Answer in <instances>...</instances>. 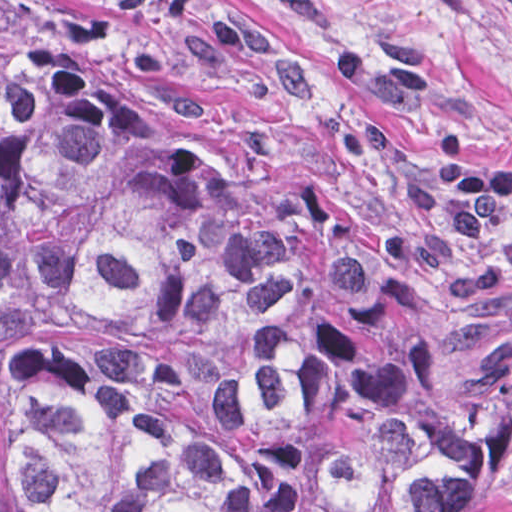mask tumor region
<instances>
[{"label": "tumor region", "mask_w": 512, "mask_h": 512, "mask_svg": "<svg viewBox=\"0 0 512 512\" xmlns=\"http://www.w3.org/2000/svg\"><path fill=\"white\" fill-rule=\"evenodd\" d=\"M347 221L242 206L0 24V512H450L512 450V179L341 137Z\"/></svg>", "instance_id": "obj_1"}]
</instances>
